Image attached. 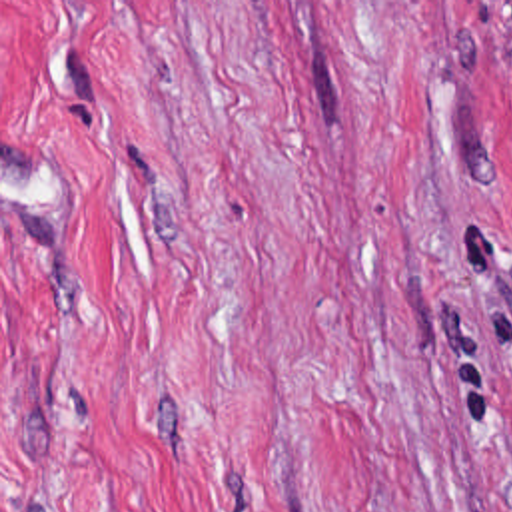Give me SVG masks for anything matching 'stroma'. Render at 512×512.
<instances>
[{
	"instance_id": "obj_1",
	"label": "stroma",
	"mask_w": 512,
	"mask_h": 512,
	"mask_svg": "<svg viewBox=\"0 0 512 512\" xmlns=\"http://www.w3.org/2000/svg\"><path fill=\"white\" fill-rule=\"evenodd\" d=\"M0 512H512V0H0Z\"/></svg>"
}]
</instances>
